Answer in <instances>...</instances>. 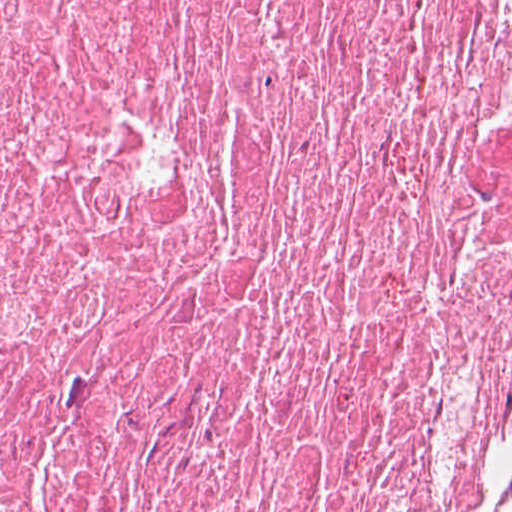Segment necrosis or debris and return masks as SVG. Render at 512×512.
I'll list each match as a JSON object with an SVG mask.
<instances>
[{"label": "necrosis or debris", "mask_w": 512, "mask_h": 512, "mask_svg": "<svg viewBox=\"0 0 512 512\" xmlns=\"http://www.w3.org/2000/svg\"><path fill=\"white\" fill-rule=\"evenodd\" d=\"M512 0H0V512H500Z\"/></svg>", "instance_id": "1"}]
</instances>
